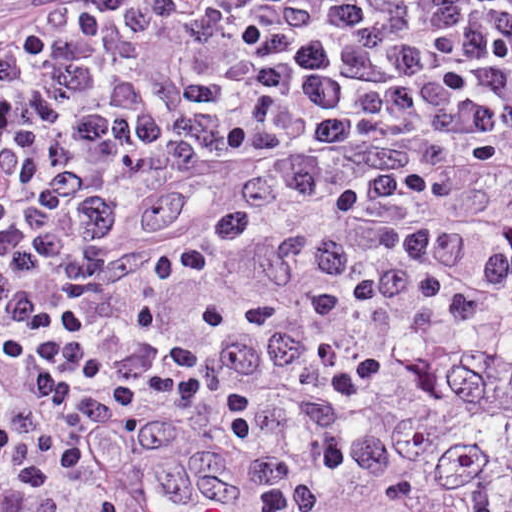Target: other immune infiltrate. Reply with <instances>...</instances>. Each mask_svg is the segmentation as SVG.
<instances>
[{
  "label": "other immune infiltrate",
  "mask_w": 512,
  "mask_h": 512,
  "mask_svg": "<svg viewBox=\"0 0 512 512\" xmlns=\"http://www.w3.org/2000/svg\"><path fill=\"white\" fill-rule=\"evenodd\" d=\"M509 314L512 253L455 290L224 386L45 512H275L377 397Z\"/></svg>",
  "instance_id": "bc1004c8"
}]
</instances>
